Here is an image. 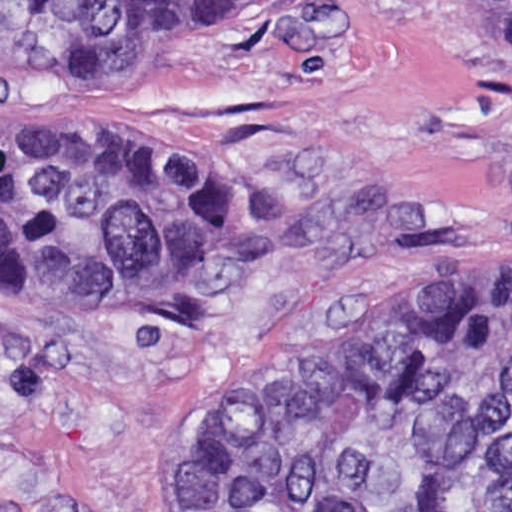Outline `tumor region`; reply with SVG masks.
Returning <instances> with one entry per match:
<instances>
[{
	"mask_svg": "<svg viewBox=\"0 0 512 512\" xmlns=\"http://www.w3.org/2000/svg\"><path fill=\"white\" fill-rule=\"evenodd\" d=\"M207 0H0V55L153 74ZM512 69V0H446ZM316 205L233 147L109 116H0V287L119 311L170 343L257 310ZM225 512H512V244L454 307L365 336L209 426Z\"/></svg>",
	"mask_w": 512,
	"mask_h": 512,
	"instance_id": "1",
	"label": "tumor region"
}]
</instances>
